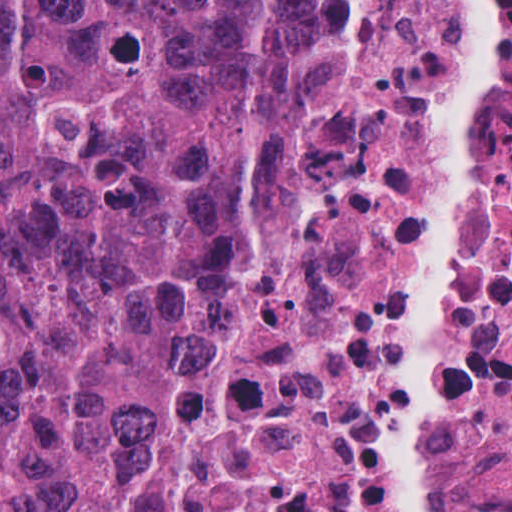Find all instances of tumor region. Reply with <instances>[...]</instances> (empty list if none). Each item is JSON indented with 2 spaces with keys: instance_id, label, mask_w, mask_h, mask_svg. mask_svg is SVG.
<instances>
[{
  "instance_id": "obj_1",
  "label": "tumor region",
  "mask_w": 512,
  "mask_h": 512,
  "mask_svg": "<svg viewBox=\"0 0 512 512\" xmlns=\"http://www.w3.org/2000/svg\"><path fill=\"white\" fill-rule=\"evenodd\" d=\"M313 0H0V512H178L207 287L290 165Z\"/></svg>"
}]
</instances>
